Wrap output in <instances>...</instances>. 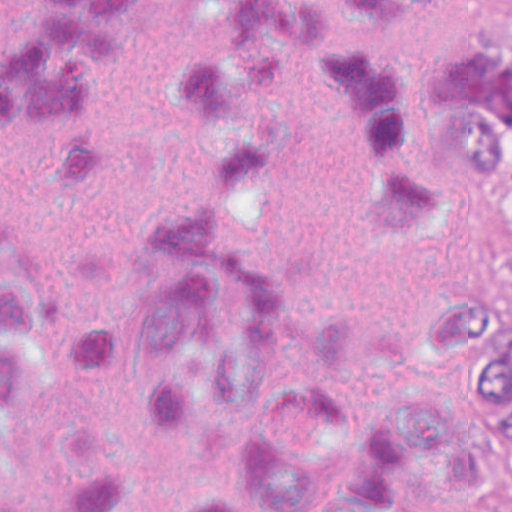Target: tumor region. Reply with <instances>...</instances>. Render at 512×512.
<instances>
[{
  "label": "tumor region",
  "mask_w": 512,
  "mask_h": 512,
  "mask_svg": "<svg viewBox=\"0 0 512 512\" xmlns=\"http://www.w3.org/2000/svg\"><path fill=\"white\" fill-rule=\"evenodd\" d=\"M512 180V39L500 49V86L484 183ZM471 332L495 404V512H512V301L471 295Z\"/></svg>",
  "instance_id": "obj_1"
}]
</instances>
